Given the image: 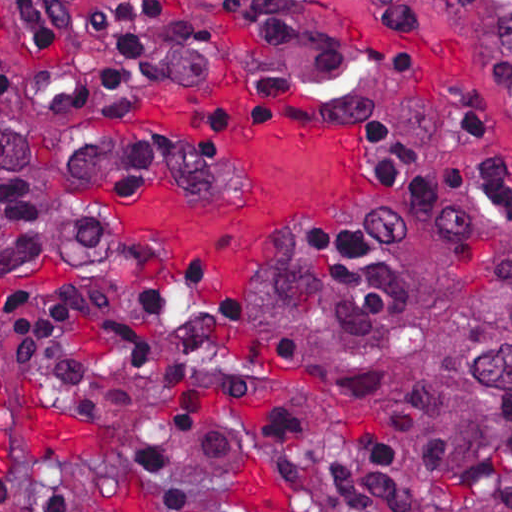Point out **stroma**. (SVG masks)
Wrapping results in <instances>:
<instances>
[{"label": "stroma", "instance_id": "obj_1", "mask_svg": "<svg viewBox=\"0 0 512 512\" xmlns=\"http://www.w3.org/2000/svg\"><path fill=\"white\" fill-rule=\"evenodd\" d=\"M418 24L396 33L369 0H169L192 45L144 85L120 94L66 93L51 76L11 0H0V46L30 89L56 105L91 148L104 224L91 254L48 284L0 291V475L64 471L102 512H172L135 475L132 448L166 453L225 501H284L270 431L253 410L217 412L179 428L133 356L107 337L128 321L164 363L194 346L163 294L136 315L106 291L149 271L168 275L201 318L245 350L304 436L331 486L333 512H359L366 441L345 438L283 369L262 318L266 295L302 278L308 257L373 211L370 192L431 210L512 216V206L422 199L384 189L366 155V196L353 208L272 240L249 308L215 296L186 255L136 234L119 201L151 182L210 205L235 207L231 162L191 128L152 119L161 86H206L239 76L246 95L301 106L321 124L383 123L410 138L512 164V0H413ZM377 11V12H376ZM257 271L249 280L248 289Z\"/></svg>", "mask_w": 512, "mask_h": 512}]
</instances>
